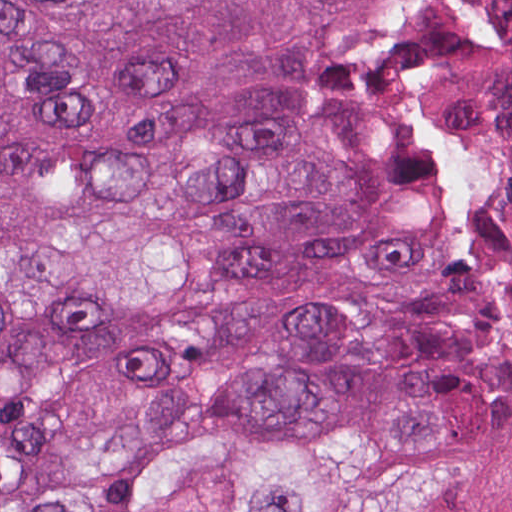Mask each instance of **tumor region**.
<instances>
[{
    "instance_id": "obj_1",
    "label": "tumor region",
    "mask_w": 512,
    "mask_h": 512,
    "mask_svg": "<svg viewBox=\"0 0 512 512\" xmlns=\"http://www.w3.org/2000/svg\"><path fill=\"white\" fill-rule=\"evenodd\" d=\"M0 512H512V0H0Z\"/></svg>"
}]
</instances>
